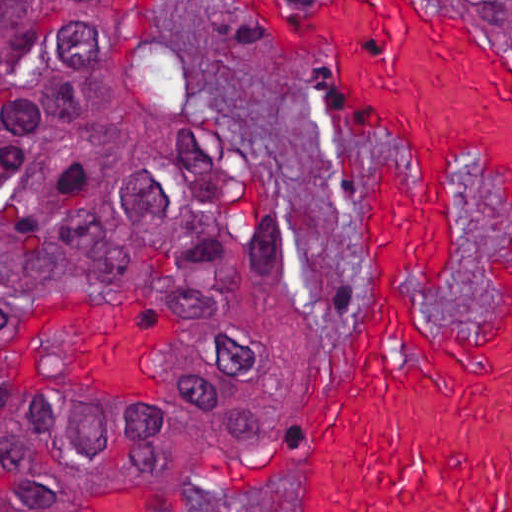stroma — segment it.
Here are the masks:
<instances>
[{
	"mask_svg": "<svg viewBox=\"0 0 512 512\" xmlns=\"http://www.w3.org/2000/svg\"><path fill=\"white\" fill-rule=\"evenodd\" d=\"M120 1L169 70L184 112L264 185L293 239V323L265 397L233 430L170 460L62 486V512H200L213 498L308 512L311 436L366 314V197L376 174L419 182L395 130L338 93L323 54L263 35L220 1H428L512 64V21L487 1Z\"/></svg>",
	"mask_w": 512,
	"mask_h": 512,
	"instance_id": "35a3bbf8",
	"label": "stroma"
}]
</instances>
